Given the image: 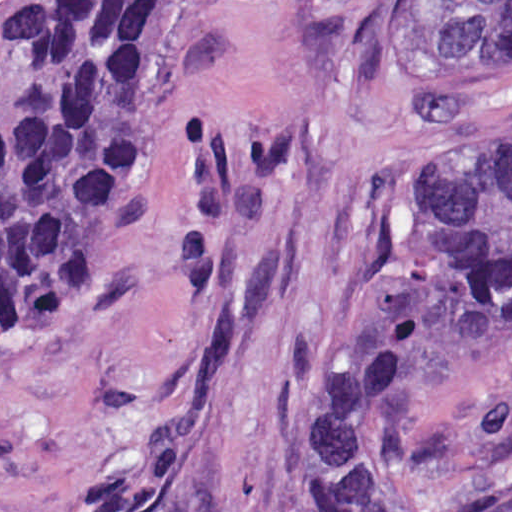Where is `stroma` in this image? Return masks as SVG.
<instances>
[{
  "label": "stroma",
  "instance_id": "1",
  "mask_svg": "<svg viewBox=\"0 0 512 512\" xmlns=\"http://www.w3.org/2000/svg\"><path fill=\"white\" fill-rule=\"evenodd\" d=\"M399 1L178 0L97 324L0 316V512H311L313 399L393 302L434 175L512 135V57L421 70ZM411 453L441 512H512V336Z\"/></svg>",
  "mask_w": 512,
  "mask_h": 512
}]
</instances>
